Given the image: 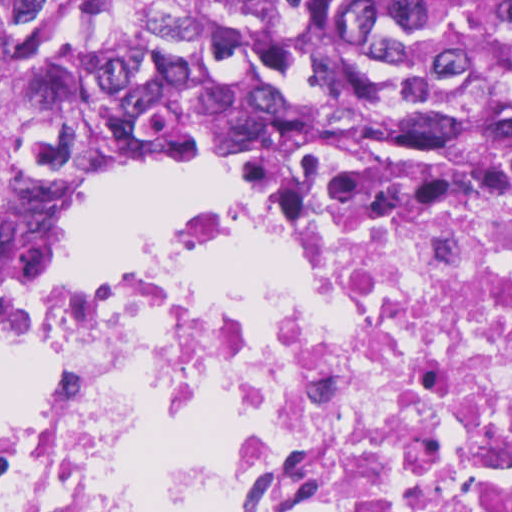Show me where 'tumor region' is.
<instances>
[{"label": "tumor region", "instance_id": "obj_1", "mask_svg": "<svg viewBox=\"0 0 512 512\" xmlns=\"http://www.w3.org/2000/svg\"><path fill=\"white\" fill-rule=\"evenodd\" d=\"M512 149V0H0V286L112 169Z\"/></svg>", "mask_w": 512, "mask_h": 512}]
</instances>
